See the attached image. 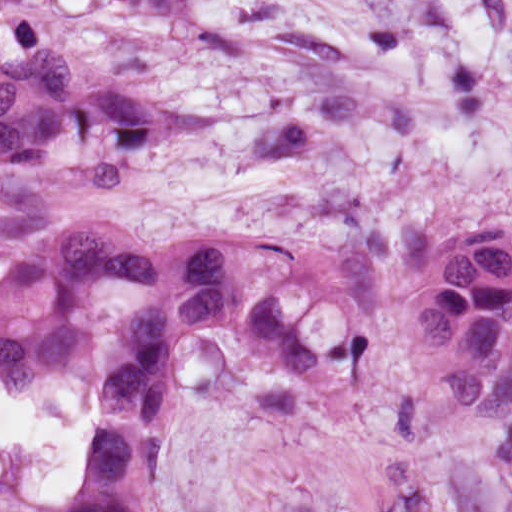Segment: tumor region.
I'll use <instances>...</instances> for the list:
<instances>
[{"label":"tumor region","instance_id":"tumor-region-1","mask_svg":"<svg viewBox=\"0 0 512 512\" xmlns=\"http://www.w3.org/2000/svg\"><path fill=\"white\" fill-rule=\"evenodd\" d=\"M511 219L466 226L432 247L409 303L404 350L453 426L512 419ZM125 290L158 298L123 325L133 366L97 396L81 496L71 512H147L172 434L175 359L188 330H238L258 355L295 372V381L269 383L255 394L257 415L272 427H313L325 407L365 392L380 326L356 329L339 345L305 349L266 284L247 302L220 246ZM112 317L99 300L1 343L0 382H88L98 329Z\"/></svg>","mask_w":512,"mask_h":512}]
</instances>
